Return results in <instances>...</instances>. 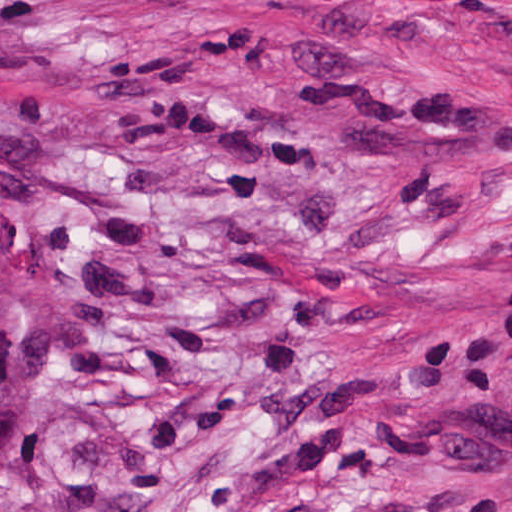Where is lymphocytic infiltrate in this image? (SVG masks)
<instances>
[{
	"instance_id": "f902f5d3",
	"label": "lymphocytic infiltrate",
	"mask_w": 512,
	"mask_h": 512,
	"mask_svg": "<svg viewBox=\"0 0 512 512\" xmlns=\"http://www.w3.org/2000/svg\"><path fill=\"white\" fill-rule=\"evenodd\" d=\"M486 481H457L400 487L386 494L378 512H469L496 491Z\"/></svg>"
}]
</instances>
